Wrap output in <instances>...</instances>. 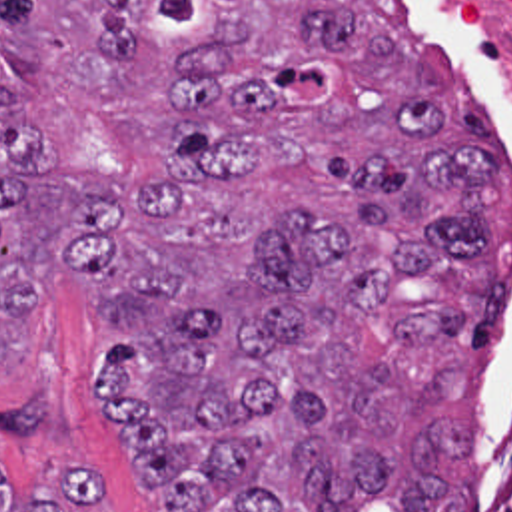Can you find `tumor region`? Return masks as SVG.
<instances>
[{
  "instance_id": "e687c5a6",
  "label": "tumor region",
  "mask_w": 512,
  "mask_h": 512,
  "mask_svg": "<svg viewBox=\"0 0 512 512\" xmlns=\"http://www.w3.org/2000/svg\"><path fill=\"white\" fill-rule=\"evenodd\" d=\"M499 127L406 0H0V370L92 277L154 512H467ZM104 470L0 512H110Z\"/></svg>"
}]
</instances>
